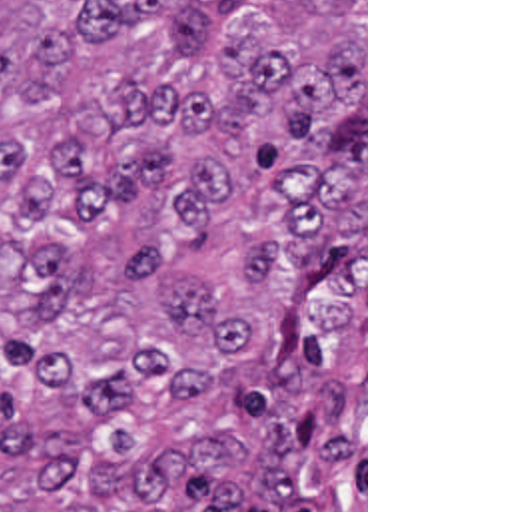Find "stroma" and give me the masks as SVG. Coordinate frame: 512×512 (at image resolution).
<instances>
[{
    "instance_id": "obj_1",
    "label": "stroma",
    "mask_w": 512,
    "mask_h": 512,
    "mask_svg": "<svg viewBox=\"0 0 512 512\" xmlns=\"http://www.w3.org/2000/svg\"><path fill=\"white\" fill-rule=\"evenodd\" d=\"M364 512H368V0H364Z\"/></svg>"
}]
</instances>
